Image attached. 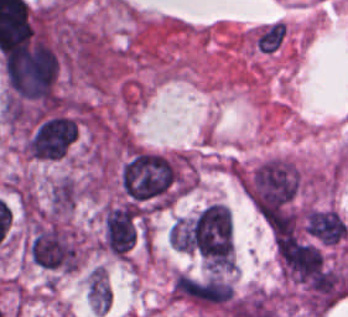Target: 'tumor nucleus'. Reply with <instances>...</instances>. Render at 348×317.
I'll list each match as a JSON object with an SVG mask.
<instances>
[{
    "label": "tumor nucleus",
    "instance_id": "obj_6",
    "mask_svg": "<svg viewBox=\"0 0 348 317\" xmlns=\"http://www.w3.org/2000/svg\"><path fill=\"white\" fill-rule=\"evenodd\" d=\"M78 121L65 113H52L32 122L24 140V152L32 158L54 160L77 138Z\"/></svg>",
    "mask_w": 348,
    "mask_h": 317
},
{
    "label": "tumor nucleus",
    "instance_id": "obj_9",
    "mask_svg": "<svg viewBox=\"0 0 348 317\" xmlns=\"http://www.w3.org/2000/svg\"><path fill=\"white\" fill-rule=\"evenodd\" d=\"M304 225L311 238L342 243L348 239V228L342 218L317 208Z\"/></svg>",
    "mask_w": 348,
    "mask_h": 317
},
{
    "label": "tumor nucleus",
    "instance_id": "obj_3",
    "mask_svg": "<svg viewBox=\"0 0 348 317\" xmlns=\"http://www.w3.org/2000/svg\"><path fill=\"white\" fill-rule=\"evenodd\" d=\"M237 178L249 203L270 218L289 205L300 175L289 159L267 156L238 169Z\"/></svg>",
    "mask_w": 348,
    "mask_h": 317
},
{
    "label": "tumor nucleus",
    "instance_id": "obj_2",
    "mask_svg": "<svg viewBox=\"0 0 348 317\" xmlns=\"http://www.w3.org/2000/svg\"><path fill=\"white\" fill-rule=\"evenodd\" d=\"M120 187L124 198L141 209L162 208L181 189L180 159L131 146L120 165Z\"/></svg>",
    "mask_w": 348,
    "mask_h": 317
},
{
    "label": "tumor nucleus",
    "instance_id": "obj_8",
    "mask_svg": "<svg viewBox=\"0 0 348 317\" xmlns=\"http://www.w3.org/2000/svg\"><path fill=\"white\" fill-rule=\"evenodd\" d=\"M233 301V288L222 275L196 278L193 305L228 309Z\"/></svg>",
    "mask_w": 348,
    "mask_h": 317
},
{
    "label": "tumor nucleus",
    "instance_id": "obj_4",
    "mask_svg": "<svg viewBox=\"0 0 348 317\" xmlns=\"http://www.w3.org/2000/svg\"><path fill=\"white\" fill-rule=\"evenodd\" d=\"M26 250L30 259L55 270H74L80 262L78 240L59 217H33Z\"/></svg>",
    "mask_w": 348,
    "mask_h": 317
},
{
    "label": "tumor nucleus",
    "instance_id": "obj_1",
    "mask_svg": "<svg viewBox=\"0 0 348 317\" xmlns=\"http://www.w3.org/2000/svg\"><path fill=\"white\" fill-rule=\"evenodd\" d=\"M4 93L12 107H41L52 100L62 58L46 36L35 33L0 56Z\"/></svg>",
    "mask_w": 348,
    "mask_h": 317
},
{
    "label": "tumor nucleus",
    "instance_id": "obj_7",
    "mask_svg": "<svg viewBox=\"0 0 348 317\" xmlns=\"http://www.w3.org/2000/svg\"><path fill=\"white\" fill-rule=\"evenodd\" d=\"M139 235V216L126 203L105 207L100 216L99 248L124 259Z\"/></svg>",
    "mask_w": 348,
    "mask_h": 317
},
{
    "label": "tumor nucleus",
    "instance_id": "obj_10",
    "mask_svg": "<svg viewBox=\"0 0 348 317\" xmlns=\"http://www.w3.org/2000/svg\"><path fill=\"white\" fill-rule=\"evenodd\" d=\"M169 243L182 251L197 249V227L192 217H178L169 228Z\"/></svg>",
    "mask_w": 348,
    "mask_h": 317
},
{
    "label": "tumor nucleus",
    "instance_id": "obj_5",
    "mask_svg": "<svg viewBox=\"0 0 348 317\" xmlns=\"http://www.w3.org/2000/svg\"><path fill=\"white\" fill-rule=\"evenodd\" d=\"M197 250L204 262L219 270H230L233 262L232 221L222 203H208L197 214Z\"/></svg>",
    "mask_w": 348,
    "mask_h": 317
}]
</instances>
